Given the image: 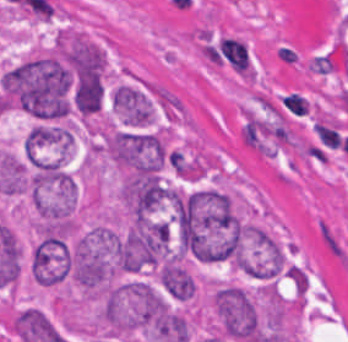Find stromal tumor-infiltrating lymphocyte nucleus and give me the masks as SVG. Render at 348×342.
Instances as JSON below:
<instances>
[{"instance_id":"obj_1","label":"stromal tumor-infiltrating lymphocyte nucleus","mask_w":348,"mask_h":342,"mask_svg":"<svg viewBox=\"0 0 348 342\" xmlns=\"http://www.w3.org/2000/svg\"><path fill=\"white\" fill-rule=\"evenodd\" d=\"M208 61L240 74H249L252 56L248 43L237 36L212 40L207 53Z\"/></svg>"},{"instance_id":"obj_2","label":"stromal tumor-infiltrating lymphocyte nucleus","mask_w":348,"mask_h":342,"mask_svg":"<svg viewBox=\"0 0 348 342\" xmlns=\"http://www.w3.org/2000/svg\"><path fill=\"white\" fill-rule=\"evenodd\" d=\"M283 111L296 117H303L309 109V101L300 90H286L279 97Z\"/></svg>"},{"instance_id":"obj_3","label":"stromal tumor-infiltrating lymphocyte nucleus","mask_w":348,"mask_h":342,"mask_svg":"<svg viewBox=\"0 0 348 342\" xmlns=\"http://www.w3.org/2000/svg\"><path fill=\"white\" fill-rule=\"evenodd\" d=\"M314 129L322 143L336 147L342 144L340 136L336 130L321 120H317Z\"/></svg>"}]
</instances>
